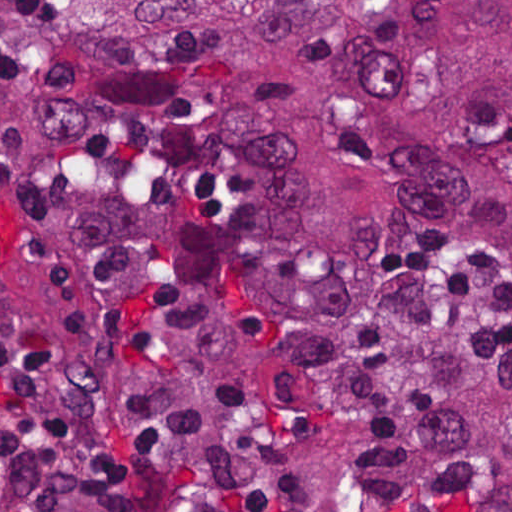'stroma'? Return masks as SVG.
Segmentation results:
<instances>
[{
  "label": "stroma",
  "mask_w": 512,
  "mask_h": 512,
  "mask_svg": "<svg viewBox=\"0 0 512 512\" xmlns=\"http://www.w3.org/2000/svg\"><path fill=\"white\" fill-rule=\"evenodd\" d=\"M150 505L166 512H250L237 498L194 485L149 460Z\"/></svg>",
  "instance_id": "stroma-1"
}]
</instances>
